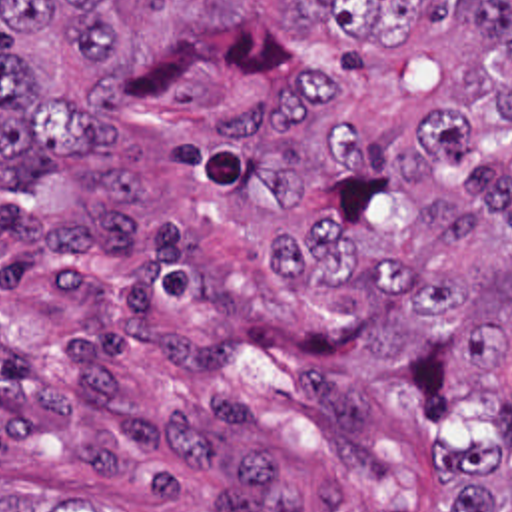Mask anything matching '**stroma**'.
Here are the masks:
<instances>
[{"label": "stroma", "instance_id": "obj_1", "mask_svg": "<svg viewBox=\"0 0 512 512\" xmlns=\"http://www.w3.org/2000/svg\"><path fill=\"white\" fill-rule=\"evenodd\" d=\"M119 128L39 196L0 180V475L103 512H452L434 439L496 425L448 322L358 282L294 294L243 198L169 164L221 142L193 104L127 98Z\"/></svg>", "mask_w": 512, "mask_h": 512}]
</instances>
